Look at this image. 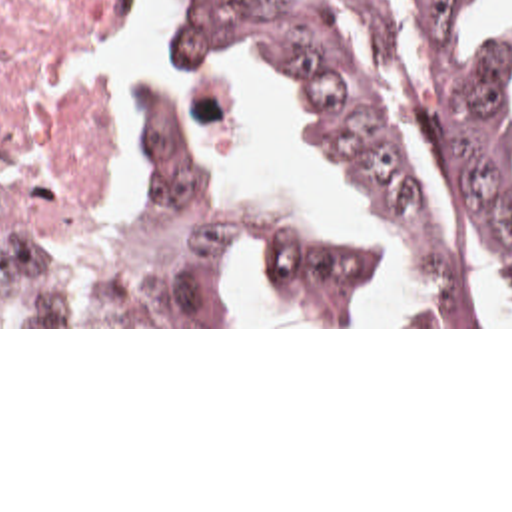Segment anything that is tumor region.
Returning a JSON list of instances; mask_svg holds the SVG:
<instances>
[{
    "label": "tumor region",
    "mask_w": 512,
    "mask_h": 512,
    "mask_svg": "<svg viewBox=\"0 0 512 512\" xmlns=\"http://www.w3.org/2000/svg\"><path fill=\"white\" fill-rule=\"evenodd\" d=\"M275 63L351 169L401 299L359 233L143 99L133 223H75L0 189V325H243L247 265L303 325H512V34L452 0H199L173 44Z\"/></svg>",
    "instance_id": "e687c5a6"
}]
</instances>
